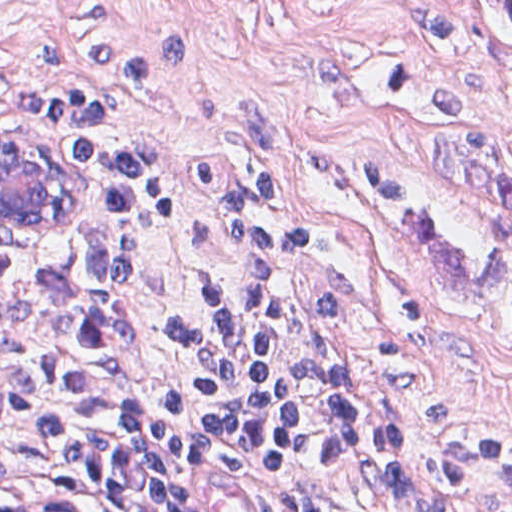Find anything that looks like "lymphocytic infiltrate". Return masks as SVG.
Returning a JSON list of instances; mask_svg holds the SVG:
<instances>
[{"instance_id":"obj_1","label":"lymphocytic infiltrate","mask_w":512,"mask_h":512,"mask_svg":"<svg viewBox=\"0 0 512 512\" xmlns=\"http://www.w3.org/2000/svg\"><path fill=\"white\" fill-rule=\"evenodd\" d=\"M0 127L53 154L116 212H158L145 141L85 92L15 78L0 56ZM239 268L200 313L207 377L183 400L142 384L148 264L169 232L61 264L0 270V475H74L146 512H428L501 473L496 446L436 474L285 384L299 286L281 215L235 204Z\"/></svg>"}]
</instances>
